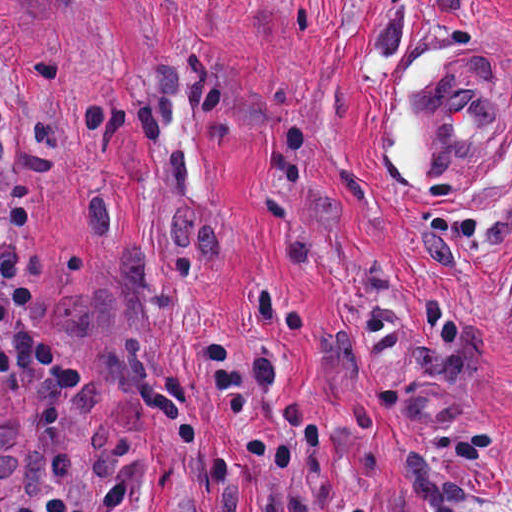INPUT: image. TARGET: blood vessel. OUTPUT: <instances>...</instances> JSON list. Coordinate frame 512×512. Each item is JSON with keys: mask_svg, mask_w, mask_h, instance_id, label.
I'll return each mask as SVG.
<instances>
[{"mask_svg": "<svg viewBox=\"0 0 512 512\" xmlns=\"http://www.w3.org/2000/svg\"><path fill=\"white\" fill-rule=\"evenodd\" d=\"M440 77L422 85L413 115L428 140L430 182H452L503 126L512 108V66L495 47L451 51Z\"/></svg>", "mask_w": 512, "mask_h": 512, "instance_id": "obj_1", "label": "blood vessel"}]
</instances>
